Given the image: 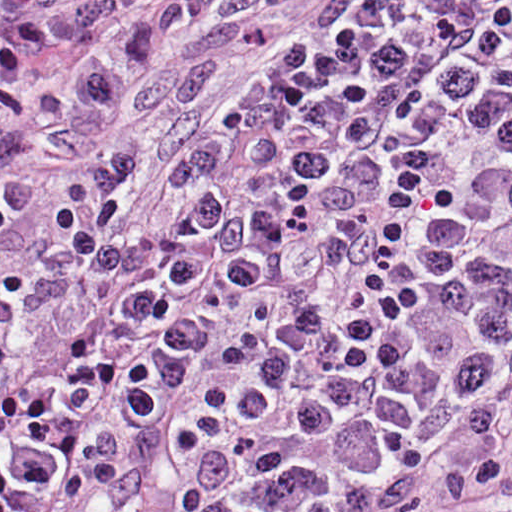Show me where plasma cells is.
<instances>
[{
    "mask_svg": "<svg viewBox=\"0 0 512 512\" xmlns=\"http://www.w3.org/2000/svg\"><path fill=\"white\" fill-rule=\"evenodd\" d=\"M219 0H0V230ZM0 267V512H335L469 322L512 320V0H318L181 154Z\"/></svg>",
    "mask_w": 512,
    "mask_h": 512,
    "instance_id": "plasma-cells-1",
    "label": "plasma cells"
}]
</instances>
